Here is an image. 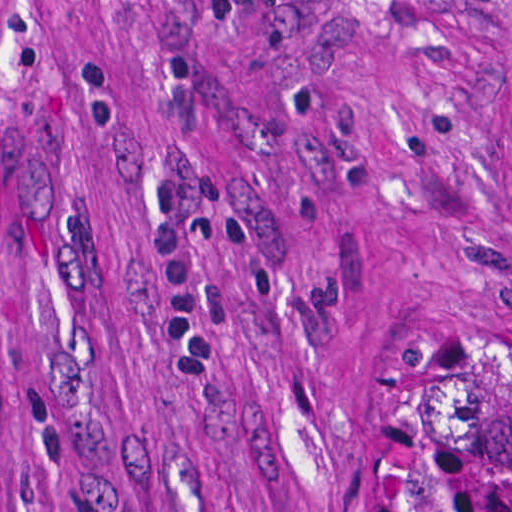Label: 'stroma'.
<instances>
[{
    "label": "stroma",
    "instance_id": "stroma-1",
    "mask_svg": "<svg viewBox=\"0 0 512 512\" xmlns=\"http://www.w3.org/2000/svg\"><path fill=\"white\" fill-rule=\"evenodd\" d=\"M425 304H512V0H0V512H376Z\"/></svg>",
    "mask_w": 512,
    "mask_h": 512
}]
</instances>
